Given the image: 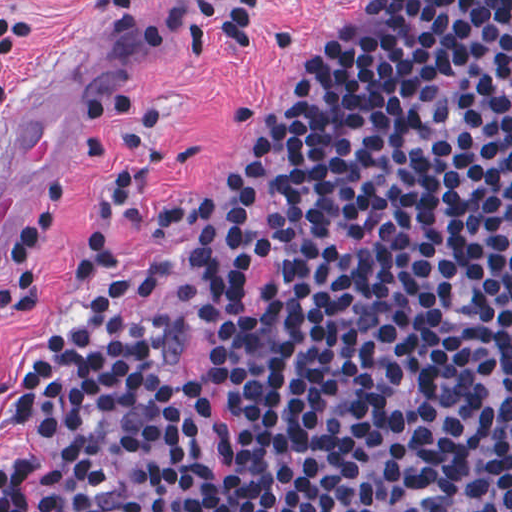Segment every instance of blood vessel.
<instances>
[{"label": "blood vessel", "mask_w": 512, "mask_h": 512, "mask_svg": "<svg viewBox=\"0 0 512 512\" xmlns=\"http://www.w3.org/2000/svg\"><path fill=\"white\" fill-rule=\"evenodd\" d=\"M144 53L111 17L0 133V242L15 210L60 178L91 122L133 90Z\"/></svg>", "instance_id": "blood-vessel-1"}]
</instances>
